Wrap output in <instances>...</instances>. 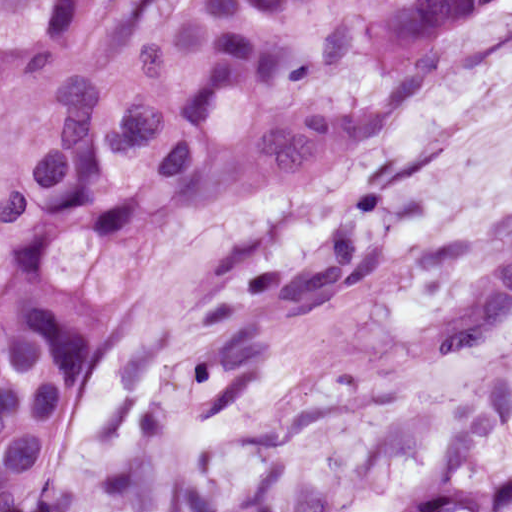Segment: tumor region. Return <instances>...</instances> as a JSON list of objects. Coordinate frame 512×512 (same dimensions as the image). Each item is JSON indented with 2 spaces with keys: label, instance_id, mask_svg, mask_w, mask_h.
<instances>
[{
  "label": "tumor region",
  "instance_id": "e687c5a6",
  "mask_svg": "<svg viewBox=\"0 0 512 512\" xmlns=\"http://www.w3.org/2000/svg\"><path fill=\"white\" fill-rule=\"evenodd\" d=\"M496 0H0V102L67 86L3 207L0 424L104 379L156 247L359 154Z\"/></svg>",
  "mask_w": 512,
  "mask_h": 512
}]
</instances>
